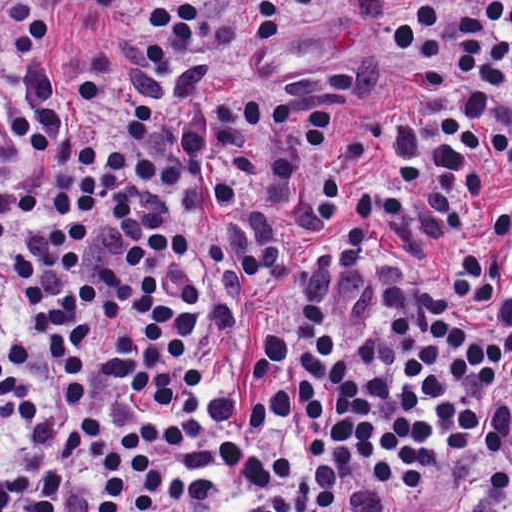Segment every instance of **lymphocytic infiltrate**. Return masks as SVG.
Here are the masks:
<instances>
[{"mask_svg": "<svg viewBox=\"0 0 512 512\" xmlns=\"http://www.w3.org/2000/svg\"><path fill=\"white\" fill-rule=\"evenodd\" d=\"M80 5L0 0V512L429 502L512 427V1L399 5L425 118L362 128L347 59L221 66L290 0Z\"/></svg>", "mask_w": 512, "mask_h": 512, "instance_id": "f902f5d3", "label": "lymphocytic infiltrate"}]
</instances>
